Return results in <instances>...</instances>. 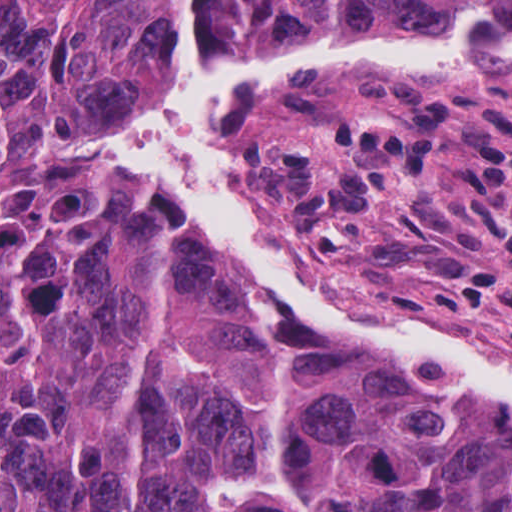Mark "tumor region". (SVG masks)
I'll use <instances>...</instances> for the list:
<instances>
[{"label":"tumor region","mask_w":512,"mask_h":512,"mask_svg":"<svg viewBox=\"0 0 512 512\" xmlns=\"http://www.w3.org/2000/svg\"><path fill=\"white\" fill-rule=\"evenodd\" d=\"M180 0H0V512H512V441L340 353L247 340L54 147L168 77ZM265 51L512 0H197Z\"/></svg>","instance_id":"obj_1"}]
</instances>
